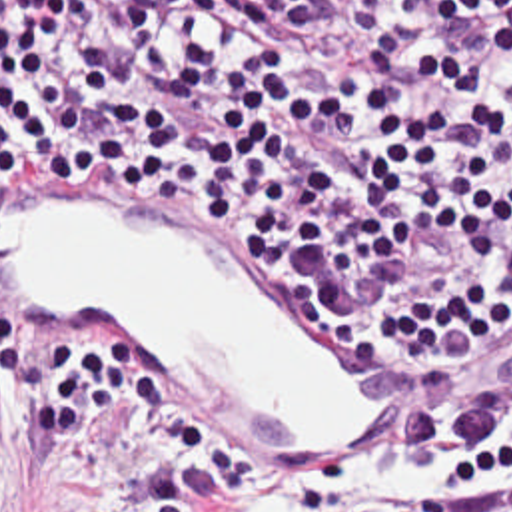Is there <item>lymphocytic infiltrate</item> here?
Listing matches in <instances>:
<instances>
[{
  "mask_svg": "<svg viewBox=\"0 0 512 512\" xmlns=\"http://www.w3.org/2000/svg\"><path fill=\"white\" fill-rule=\"evenodd\" d=\"M114 193L347 331L373 425L300 469L198 415L128 317L0 285V385L48 451L140 405L134 512H512V0H0V209Z\"/></svg>",
  "mask_w": 512,
  "mask_h": 512,
  "instance_id": "1",
  "label": "lymphocytic infiltrate"
}]
</instances>
